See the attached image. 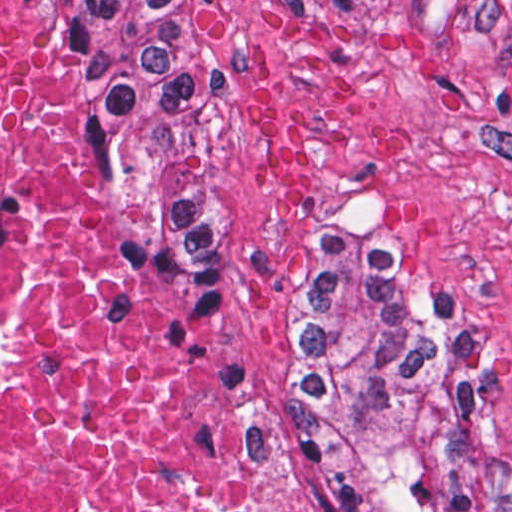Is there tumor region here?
Wrapping results in <instances>:
<instances>
[{"mask_svg":"<svg viewBox=\"0 0 512 512\" xmlns=\"http://www.w3.org/2000/svg\"><path fill=\"white\" fill-rule=\"evenodd\" d=\"M100 99L106 168L169 293L226 359L263 440L293 465L308 512H478L492 478L476 369L394 300L382 238L337 201L299 281L288 377L251 402L212 317L201 258L215 0H75Z\"/></svg>","mask_w":512,"mask_h":512,"instance_id":"tumor-region-1","label":"tumor region"}]
</instances>
